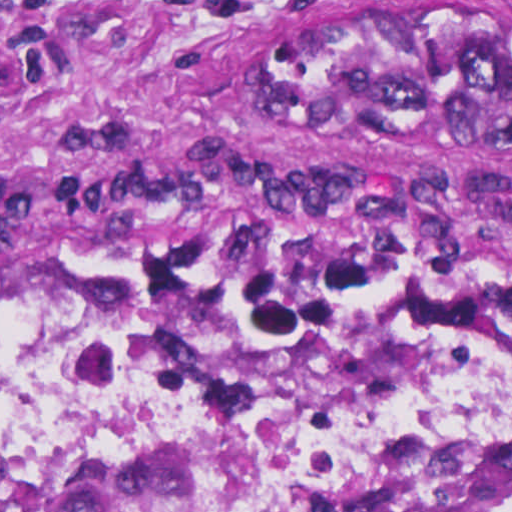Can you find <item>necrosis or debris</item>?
I'll return each instance as SVG.
<instances>
[{"label": "necrosis or debris", "mask_w": 512, "mask_h": 512, "mask_svg": "<svg viewBox=\"0 0 512 512\" xmlns=\"http://www.w3.org/2000/svg\"><path fill=\"white\" fill-rule=\"evenodd\" d=\"M375 386L259 382L144 296L0 306V460L29 465L226 461L265 512H340L420 454L512 476V370L402 367Z\"/></svg>", "instance_id": "necrosis-or-debris-1"}]
</instances>
